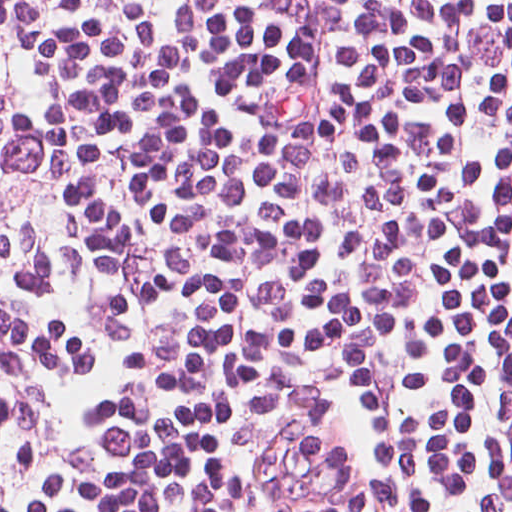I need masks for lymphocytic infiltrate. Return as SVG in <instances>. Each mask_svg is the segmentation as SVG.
Returning a JSON list of instances; mask_svg holds the SVG:
<instances>
[{"mask_svg":"<svg viewBox=\"0 0 512 512\" xmlns=\"http://www.w3.org/2000/svg\"><path fill=\"white\" fill-rule=\"evenodd\" d=\"M248 370L512 512V0H0V512H228Z\"/></svg>","mask_w":512,"mask_h":512,"instance_id":"obj_1","label":"lymphocytic infiltrate"}]
</instances>
